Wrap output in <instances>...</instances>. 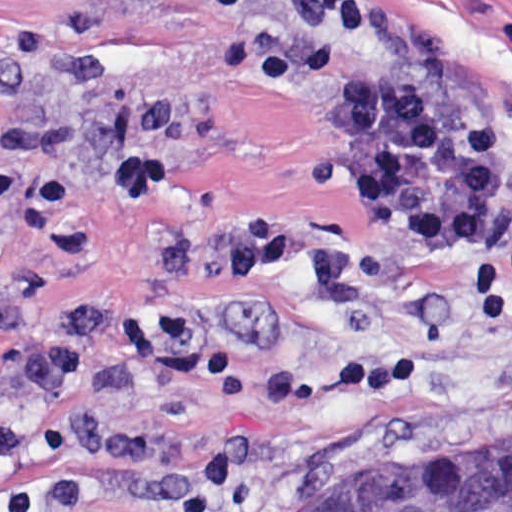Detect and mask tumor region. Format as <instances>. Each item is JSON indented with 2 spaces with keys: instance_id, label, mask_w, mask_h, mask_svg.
<instances>
[{
  "instance_id": "obj_1",
  "label": "tumor region",
  "mask_w": 512,
  "mask_h": 512,
  "mask_svg": "<svg viewBox=\"0 0 512 512\" xmlns=\"http://www.w3.org/2000/svg\"><path fill=\"white\" fill-rule=\"evenodd\" d=\"M287 512H512V455L454 471H376L301 493Z\"/></svg>"
}]
</instances>
